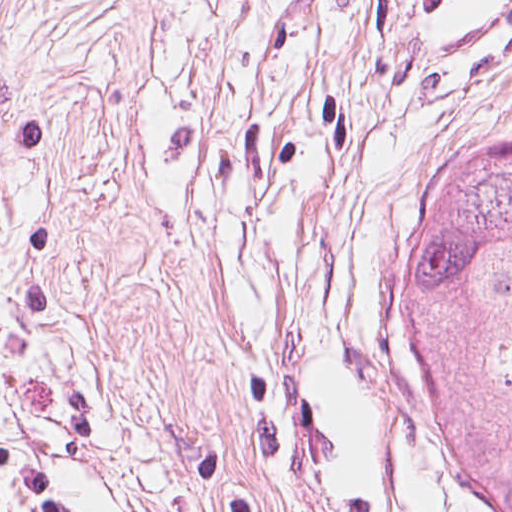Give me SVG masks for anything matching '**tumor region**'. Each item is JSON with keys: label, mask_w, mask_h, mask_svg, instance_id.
I'll return each instance as SVG.
<instances>
[{"label": "tumor region", "mask_w": 512, "mask_h": 512, "mask_svg": "<svg viewBox=\"0 0 512 512\" xmlns=\"http://www.w3.org/2000/svg\"><path fill=\"white\" fill-rule=\"evenodd\" d=\"M384 324L441 472L472 512H512V120L427 157Z\"/></svg>", "instance_id": "1"}]
</instances>
